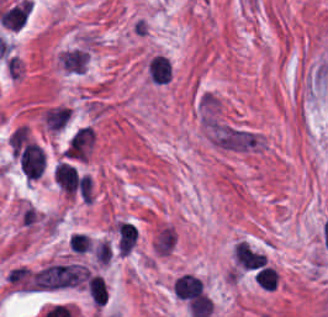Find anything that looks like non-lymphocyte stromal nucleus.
<instances>
[{"label":"non-lymphocyte stromal nucleus","instance_id":"non-lymphocyte-stromal-nucleus-1","mask_svg":"<svg viewBox=\"0 0 328 317\" xmlns=\"http://www.w3.org/2000/svg\"><path fill=\"white\" fill-rule=\"evenodd\" d=\"M88 270L76 263H50L34 275L41 289H57L77 285L86 277Z\"/></svg>","mask_w":328,"mask_h":317},{"label":"non-lymphocyte stromal nucleus","instance_id":"non-lymphocyte-stromal-nucleus-2","mask_svg":"<svg viewBox=\"0 0 328 317\" xmlns=\"http://www.w3.org/2000/svg\"><path fill=\"white\" fill-rule=\"evenodd\" d=\"M87 290L96 305H103L106 300V286L102 275L89 273L86 278Z\"/></svg>","mask_w":328,"mask_h":317}]
</instances>
